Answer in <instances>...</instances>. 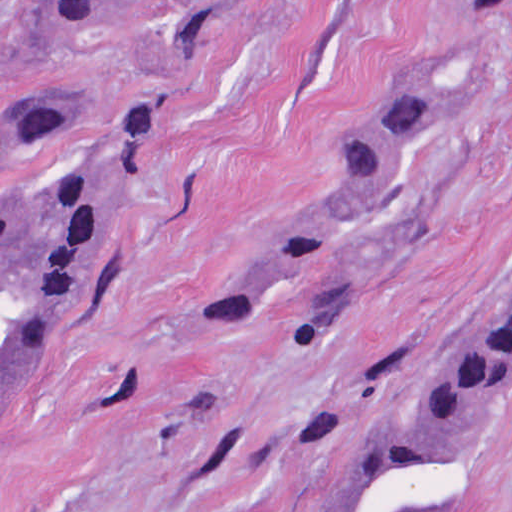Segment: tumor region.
I'll use <instances>...</instances> for the list:
<instances>
[{"instance_id":"1","label":"tumor region","mask_w":512,"mask_h":512,"mask_svg":"<svg viewBox=\"0 0 512 512\" xmlns=\"http://www.w3.org/2000/svg\"><path fill=\"white\" fill-rule=\"evenodd\" d=\"M87 15H126L178 0H71ZM512 8V0H485ZM428 105L422 87H388L346 147L325 214L220 286L192 328L237 331L300 281L298 330L335 286V237L376 189L396 144ZM141 195V166L72 149V118L47 101L21 107L0 147V433L42 381L65 330L121 248ZM512 363V287L419 390L374 427L318 512H432L479 407Z\"/></svg>"}]
</instances>
